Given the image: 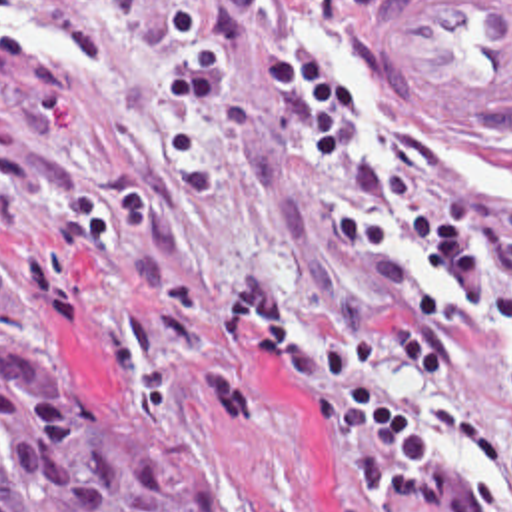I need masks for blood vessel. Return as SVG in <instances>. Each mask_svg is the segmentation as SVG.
<instances>
[{"label":"blood vessel","mask_w":512,"mask_h":512,"mask_svg":"<svg viewBox=\"0 0 512 512\" xmlns=\"http://www.w3.org/2000/svg\"><path fill=\"white\" fill-rule=\"evenodd\" d=\"M388 62L423 102L512 124V0H398Z\"/></svg>","instance_id":"blood-vessel-1"}]
</instances>
